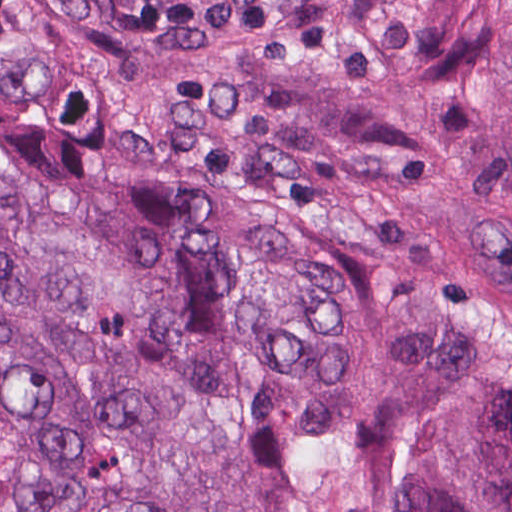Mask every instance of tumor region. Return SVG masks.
<instances>
[{
  "mask_svg": "<svg viewBox=\"0 0 512 512\" xmlns=\"http://www.w3.org/2000/svg\"><path fill=\"white\" fill-rule=\"evenodd\" d=\"M267 1L0 0V512H512V0L287 1L186 378Z\"/></svg>",
  "mask_w": 512,
  "mask_h": 512,
  "instance_id": "tumor-region-1",
  "label": "tumor region"
}]
</instances>
